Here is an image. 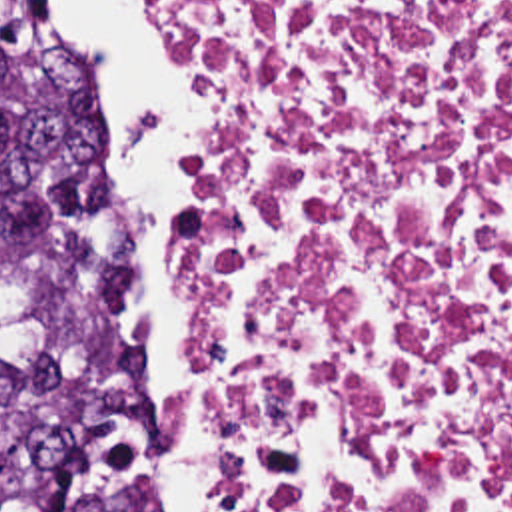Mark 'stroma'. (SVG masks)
I'll use <instances>...</instances> for the list:
<instances>
[{"label": "stroma", "instance_id": "1", "mask_svg": "<svg viewBox=\"0 0 512 512\" xmlns=\"http://www.w3.org/2000/svg\"><path fill=\"white\" fill-rule=\"evenodd\" d=\"M154 2H156L158 10H160V14H162L164 22H166V24H168V28L172 30V34L178 38V34H176V30H174V26H172L170 18L166 16L164 8L160 6V2H158V0H154ZM178 42H180V40H178ZM208 138H210V88H208ZM144 426H146V424H144ZM210 512H214V445H212V436H210Z\"/></svg>", "mask_w": 512, "mask_h": 512}]
</instances>
